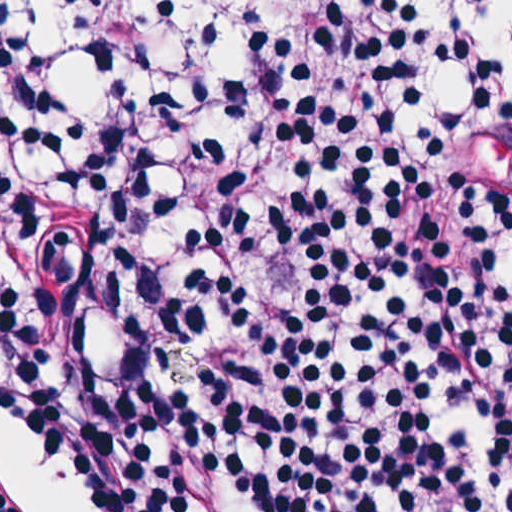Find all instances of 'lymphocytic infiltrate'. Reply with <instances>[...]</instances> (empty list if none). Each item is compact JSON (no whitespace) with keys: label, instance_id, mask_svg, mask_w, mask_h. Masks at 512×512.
Returning a JSON list of instances; mask_svg holds the SVG:
<instances>
[{"label":"lymphocytic infiltrate","instance_id":"obj_1","mask_svg":"<svg viewBox=\"0 0 512 512\" xmlns=\"http://www.w3.org/2000/svg\"><path fill=\"white\" fill-rule=\"evenodd\" d=\"M248 1L145 105L11 0L1 408L80 512H512V104L428 108L397 0Z\"/></svg>","mask_w":512,"mask_h":512}]
</instances>
